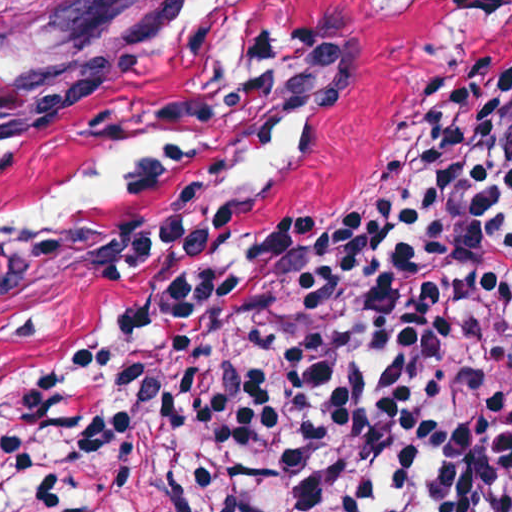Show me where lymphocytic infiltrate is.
Listing matches in <instances>:
<instances>
[{
	"instance_id": "1",
	"label": "lymphocytic infiltrate",
	"mask_w": 512,
	"mask_h": 512,
	"mask_svg": "<svg viewBox=\"0 0 512 512\" xmlns=\"http://www.w3.org/2000/svg\"><path fill=\"white\" fill-rule=\"evenodd\" d=\"M456 52L383 167L307 216L127 202L102 300L16 389L169 401L180 512L512 511V0H431ZM0 512H156L125 414L55 442Z\"/></svg>"
}]
</instances>
